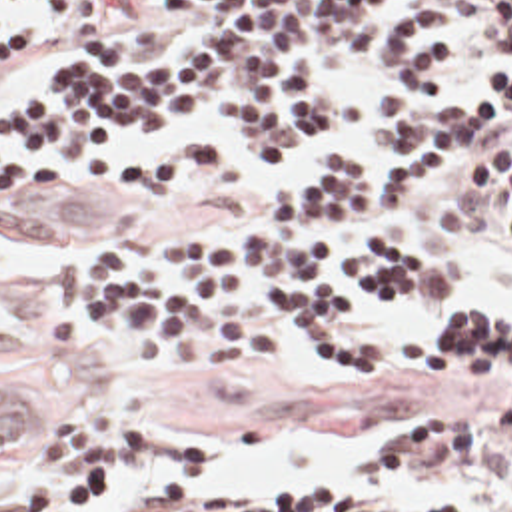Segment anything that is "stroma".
Returning a JSON list of instances; mask_svg holds the SVG:
<instances>
[{
	"mask_svg": "<svg viewBox=\"0 0 512 512\" xmlns=\"http://www.w3.org/2000/svg\"><path fill=\"white\" fill-rule=\"evenodd\" d=\"M501 51L477 47L457 61L446 91L457 103H477L489 67ZM52 59L0 87V103L40 81ZM314 71L354 91L352 115L304 144L288 158L260 164L234 152L218 129V109L204 103L186 119L166 127L108 125L104 131L132 146L112 164H62L0 133V156L36 164L56 178V208H0V230L12 232L58 258L96 242L118 238H172L212 230L246 238L260 208L278 184L312 158L350 142L364 144L356 119L398 87L406 85L396 61L376 49H342L318 55ZM380 164V158H378ZM465 160L452 156L430 166L416 198L398 214L396 228L412 234L444 260L503 246L473 230H454L430 210V198L463 174ZM44 280H28L0 266V304L24 322V346L0 364H24L50 384V418L88 416L196 422L214 440H242L264 432L344 430L356 426H402L428 410H471L485 402L512 400V386L471 382H412L358 374L360 382H304L258 360H202L178 348L144 354L118 352L76 330L58 340L38 320ZM276 314V312H274ZM512 314V312H511ZM286 320L284 314H276ZM356 318L384 324L368 304ZM300 328L302 320L294 318ZM386 326V324H384ZM290 340H296L290 336ZM142 464L108 492L80 504L76 512H120L152 498L138 478ZM36 470L20 450L0 464V512H8L14 486ZM459 480L457 472H434ZM473 496V490H471ZM416 512L418 506H390ZM475 512H493L481 498Z\"/></svg>",
	"mask_w": 512,
	"mask_h": 512,
	"instance_id": "35a3bbf8",
	"label": "stroma"
}]
</instances>
